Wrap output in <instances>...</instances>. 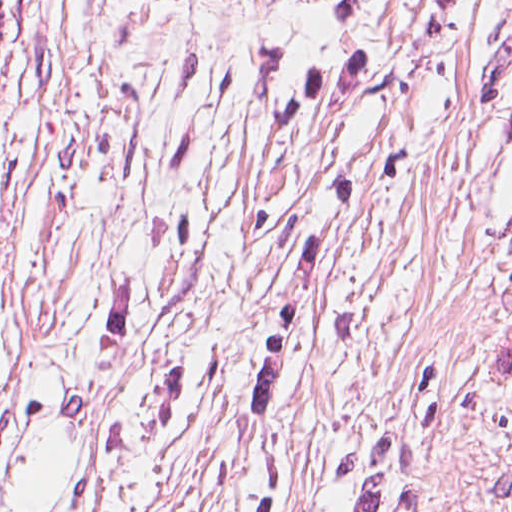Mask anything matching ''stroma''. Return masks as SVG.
Masks as SVG:
<instances>
[{"label": "stroma", "instance_id": "35a3bbf8", "mask_svg": "<svg viewBox=\"0 0 512 512\" xmlns=\"http://www.w3.org/2000/svg\"><path fill=\"white\" fill-rule=\"evenodd\" d=\"M97 0H0V449Z\"/></svg>", "mask_w": 512, "mask_h": 512}]
</instances>
